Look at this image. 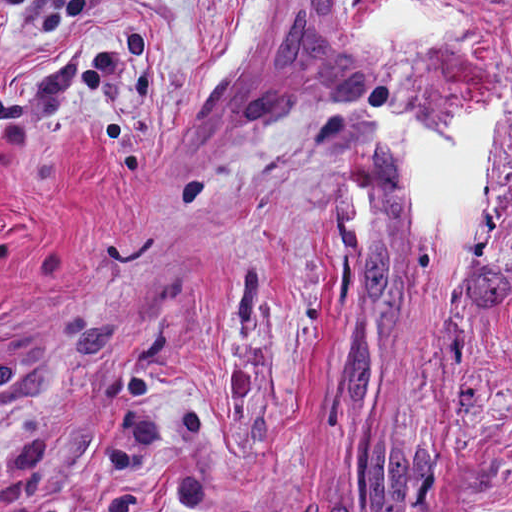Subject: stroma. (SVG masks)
Listing matches in <instances>:
<instances>
[{"label":"stroma","instance_id":"stroma-1","mask_svg":"<svg viewBox=\"0 0 512 512\" xmlns=\"http://www.w3.org/2000/svg\"><path fill=\"white\" fill-rule=\"evenodd\" d=\"M392 1L280 0L206 88L238 0H0V512H512V104L440 251L368 109L512 87V0L380 53Z\"/></svg>","mask_w":512,"mask_h":512}]
</instances>
